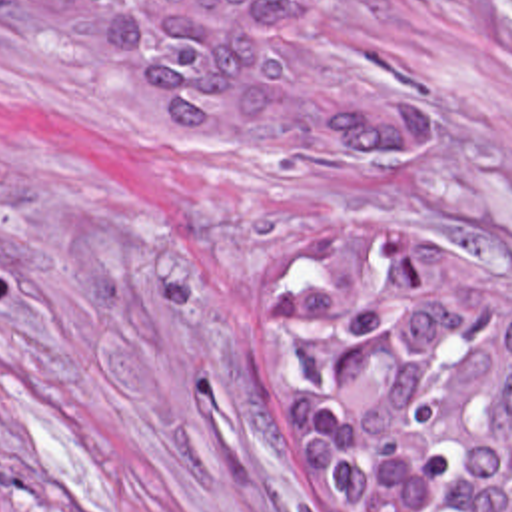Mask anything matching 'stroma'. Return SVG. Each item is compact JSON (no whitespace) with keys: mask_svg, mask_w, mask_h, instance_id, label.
Returning a JSON list of instances; mask_svg holds the SVG:
<instances>
[{"mask_svg":"<svg viewBox=\"0 0 512 512\" xmlns=\"http://www.w3.org/2000/svg\"><path fill=\"white\" fill-rule=\"evenodd\" d=\"M438 111L387 181H243L147 135L45 0H0V512H315L257 357L277 263L416 233L512 265V0H315Z\"/></svg>","mask_w":512,"mask_h":512,"instance_id":"35a3bbf8","label":"stroma"}]
</instances>
